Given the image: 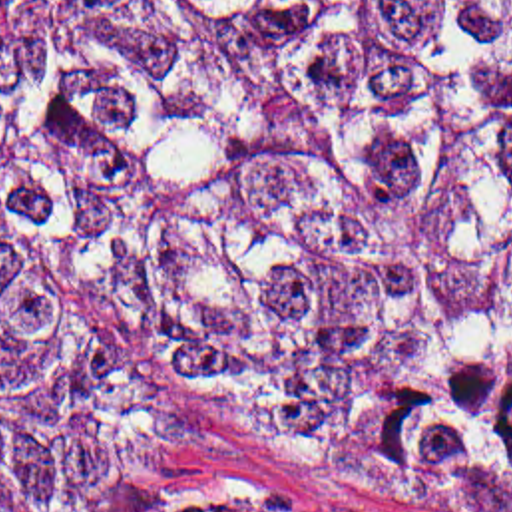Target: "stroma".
<instances>
[{
    "mask_svg": "<svg viewBox=\"0 0 512 512\" xmlns=\"http://www.w3.org/2000/svg\"><path fill=\"white\" fill-rule=\"evenodd\" d=\"M67 312L178 441L27 512H512V489L397 481L312 433L244 415L121 312L95 302Z\"/></svg>",
    "mask_w": 512,
    "mask_h": 512,
    "instance_id": "obj_1",
    "label": "stroma"
}]
</instances>
